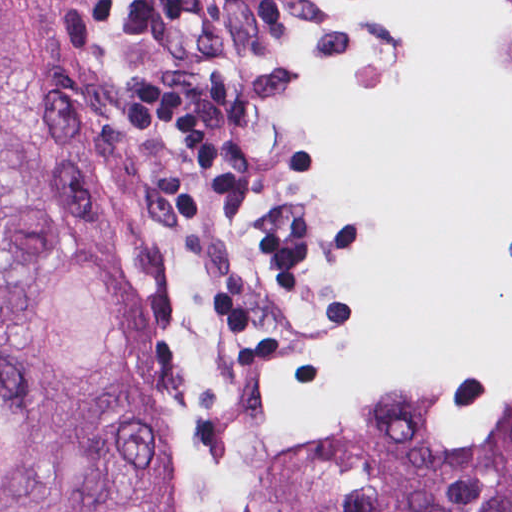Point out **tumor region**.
I'll list each match as a JSON object with an SVG mask.
<instances>
[{"label": "tumor region", "mask_w": 512, "mask_h": 512, "mask_svg": "<svg viewBox=\"0 0 512 512\" xmlns=\"http://www.w3.org/2000/svg\"><path fill=\"white\" fill-rule=\"evenodd\" d=\"M287 58V0H0V512H187L100 280L88 102ZM297 512H512V428L464 449L402 382L321 422Z\"/></svg>", "instance_id": "obj_1"}]
</instances>
